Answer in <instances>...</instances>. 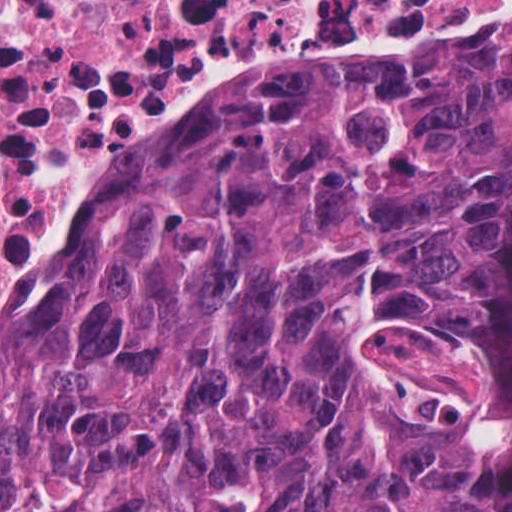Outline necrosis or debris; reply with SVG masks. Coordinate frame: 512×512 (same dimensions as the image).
I'll return each mask as SVG.
<instances>
[{
	"mask_svg": "<svg viewBox=\"0 0 512 512\" xmlns=\"http://www.w3.org/2000/svg\"><path fill=\"white\" fill-rule=\"evenodd\" d=\"M501 0H0V243L51 165L218 69L256 32L342 34Z\"/></svg>",
	"mask_w": 512,
	"mask_h": 512,
	"instance_id": "1",
	"label": "necrosis or debris"
}]
</instances>
